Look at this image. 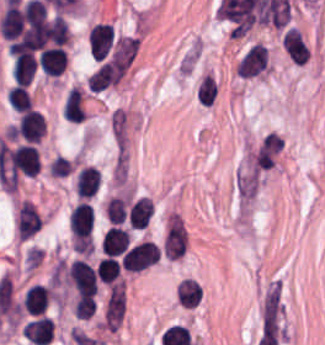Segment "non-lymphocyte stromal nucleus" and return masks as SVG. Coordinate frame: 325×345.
<instances>
[{
    "instance_id": "non-lymphocyte-stromal-nucleus-1",
    "label": "non-lymphocyte stromal nucleus",
    "mask_w": 325,
    "mask_h": 345,
    "mask_svg": "<svg viewBox=\"0 0 325 345\" xmlns=\"http://www.w3.org/2000/svg\"><path fill=\"white\" fill-rule=\"evenodd\" d=\"M124 312V287L111 283L108 287L102 313L103 325L106 329H117Z\"/></svg>"
},
{
    "instance_id": "non-lymphocyte-stromal-nucleus-2",
    "label": "non-lymphocyte stromal nucleus",
    "mask_w": 325,
    "mask_h": 345,
    "mask_svg": "<svg viewBox=\"0 0 325 345\" xmlns=\"http://www.w3.org/2000/svg\"><path fill=\"white\" fill-rule=\"evenodd\" d=\"M281 309L279 281H272L261 303L262 324Z\"/></svg>"
}]
</instances>
